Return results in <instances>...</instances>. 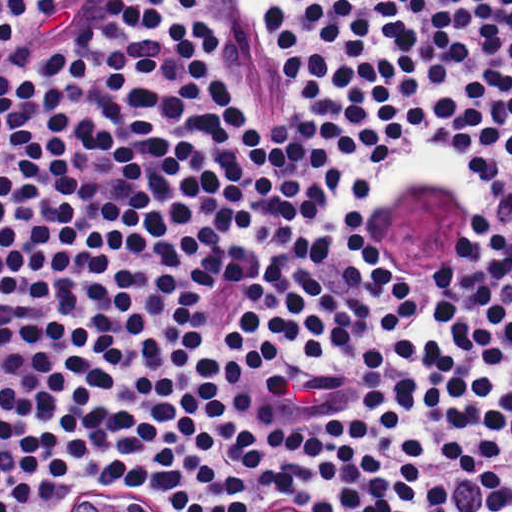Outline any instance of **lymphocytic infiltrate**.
I'll use <instances>...</instances> for the list:
<instances>
[{
  "label": "lymphocytic infiltrate",
  "instance_id": "obj_1",
  "mask_svg": "<svg viewBox=\"0 0 512 512\" xmlns=\"http://www.w3.org/2000/svg\"><path fill=\"white\" fill-rule=\"evenodd\" d=\"M110 1L0 0V512H512V0Z\"/></svg>",
  "mask_w": 512,
  "mask_h": 512
}]
</instances>
